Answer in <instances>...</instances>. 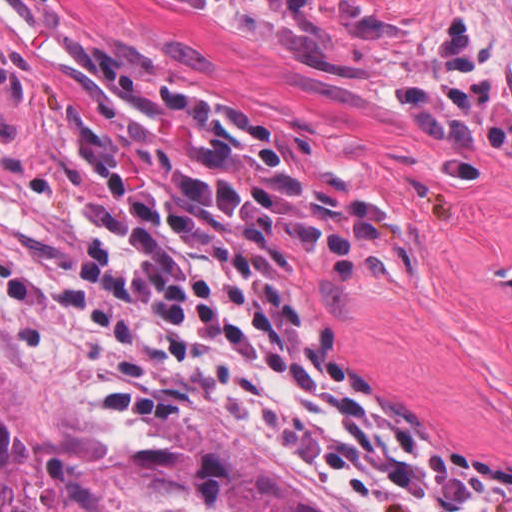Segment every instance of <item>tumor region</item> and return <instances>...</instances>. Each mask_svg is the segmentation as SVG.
<instances>
[{"label":"tumor region","instance_id":"e687c5a6","mask_svg":"<svg viewBox=\"0 0 512 512\" xmlns=\"http://www.w3.org/2000/svg\"><path fill=\"white\" fill-rule=\"evenodd\" d=\"M332 74L382 84L426 137H512V91L351 0H218ZM158 437L130 454L120 484L148 512L216 504L223 512H323L263 454L234 434L146 414ZM0 512H33V457L0 363Z\"/></svg>","mask_w":512,"mask_h":512}]
</instances>
